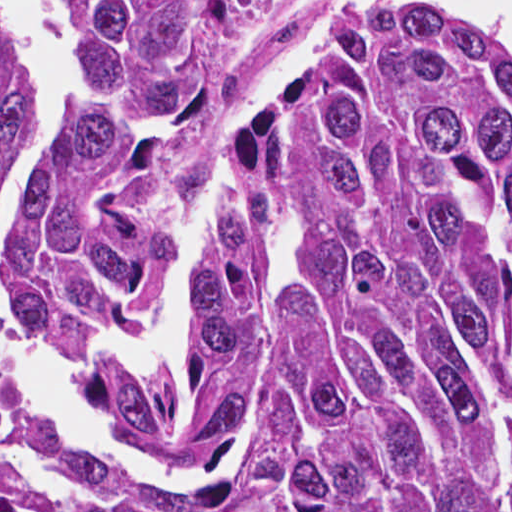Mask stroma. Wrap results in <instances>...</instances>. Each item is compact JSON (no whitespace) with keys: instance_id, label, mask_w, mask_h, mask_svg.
<instances>
[{"instance_id":"obj_1","label":"stroma","mask_w":512,"mask_h":512,"mask_svg":"<svg viewBox=\"0 0 512 512\" xmlns=\"http://www.w3.org/2000/svg\"><path fill=\"white\" fill-rule=\"evenodd\" d=\"M330 1L274 0L259 33L231 75L225 96L230 114L231 101L240 81L288 49ZM327 71L304 84L282 106L267 109L263 118L313 98Z\"/></svg>"}]
</instances>
